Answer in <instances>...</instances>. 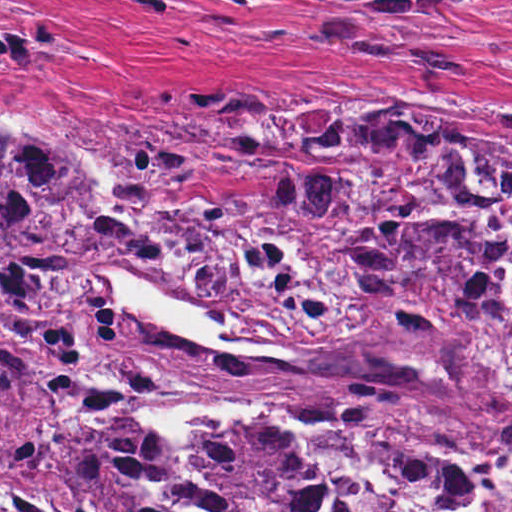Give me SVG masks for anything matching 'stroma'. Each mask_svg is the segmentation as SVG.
<instances>
[{"label":"stroma","mask_w":512,"mask_h":512,"mask_svg":"<svg viewBox=\"0 0 512 512\" xmlns=\"http://www.w3.org/2000/svg\"><path fill=\"white\" fill-rule=\"evenodd\" d=\"M9 1L63 19L0 14V21L49 22L81 53L0 76V123L40 121L68 131L100 157L108 189L135 211L115 143L130 121L201 97L215 99L233 121L326 90L391 108L379 112L419 126L427 125L407 113L512 128V7L456 2L344 16L311 0ZM146 235L147 247L113 253L83 277L121 309L98 274L142 276L152 244ZM125 315L116 339L105 343L94 411L146 422L160 471L143 512H159L156 488L175 477L178 457L143 403L111 379L129 339L132 317ZM0 512L99 511L0 470Z\"/></svg>","instance_id":"obj_1"}]
</instances>
